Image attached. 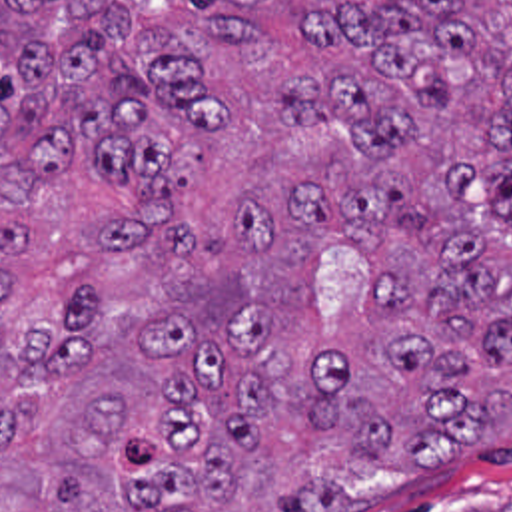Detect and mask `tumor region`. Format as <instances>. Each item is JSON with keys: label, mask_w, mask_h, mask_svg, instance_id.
Returning <instances> with one entry per match:
<instances>
[{"label": "tumor region", "mask_w": 512, "mask_h": 512, "mask_svg": "<svg viewBox=\"0 0 512 512\" xmlns=\"http://www.w3.org/2000/svg\"><path fill=\"white\" fill-rule=\"evenodd\" d=\"M0 512H512V0H0Z\"/></svg>", "instance_id": "tumor-region-1"}]
</instances>
